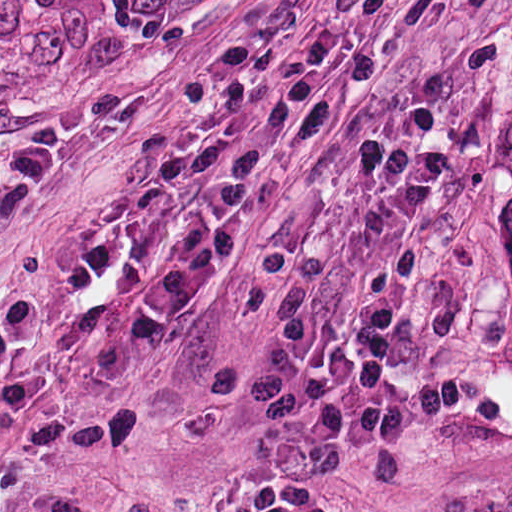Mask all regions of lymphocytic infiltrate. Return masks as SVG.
Masks as SVG:
<instances>
[{
	"label": "lymphocytic infiltrate",
	"instance_id": "obj_1",
	"mask_svg": "<svg viewBox=\"0 0 512 512\" xmlns=\"http://www.w3.org/2000/svg\"><path fill=\"white\" fill-rule=\"evenodd\" d=\"M54 168L24 139L0 181L31 194ZM365 266L362 287L327 325L288 336L272 358L280 419L242 492L217 512H344L340 467L399 432L429 399L401 289L448 196L445 131L402 114L356 137L333 170ZM482 512H512V484Z\"/></svg>",
	"mask_w": 512,
	"mask_h": 512
}]
</instances>
